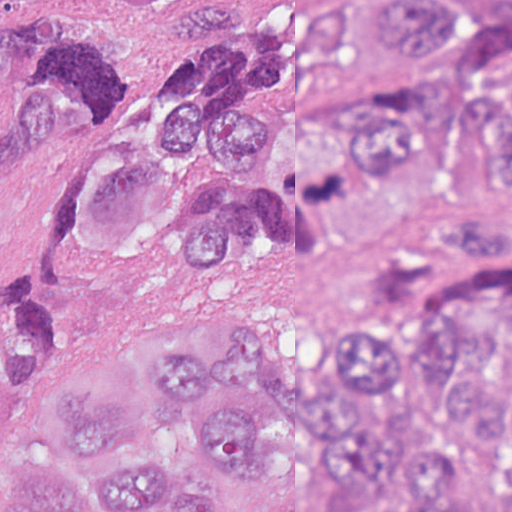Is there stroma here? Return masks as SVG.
I'll return each instance as SVG.
<instances>
[{"instance_id": "stroma-1", "label": "stroma", "mask_w": 512, "mask_h": 512, "mask_svg": "<svg viewBox=\"0 0 512 512\" xmlns=\"http://www.w3.org/2000/svg\"><path fill=\"white\" fill-rule=\"evenodd\" d=\"M0 1H512V0H0ZM489 265H512V254ZM446 267L393 302H347L272 255L196 271L148 275L104 291L72 317L64 361L41 390L40 432L59 450L84 408L109 384L136 406L142 439L165 453L195 443L189 417L163 403L151 375V319L175 296L210 288L236 296L291 340L320 347L345 330L398 331L437 309ZM270 427L259 456L228 476L233 512H418L345 493L340 465L292 434L265 385H234ZM481 473L465 512H512V420L492 444H466ZM106 482L87 479V512Z\"/></svg>"}]
</instances>
